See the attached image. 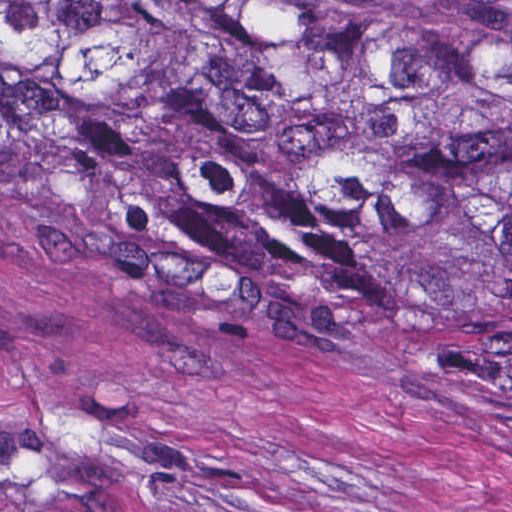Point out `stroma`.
Returning <instances> with one entry per match:
<instances>
[{
	"mask_svg": "<svg viewBox=\"0 0 512 512\" xmlns=\"http://www.w3.org/2000/svg\"><path fill=\"white\" fill-rule=\"evenodd\" d=\"M0 512H512V387L372 322L214 319L11 195L0 0Z\"/></svg>",
	"mask_w": 512,
	"mask_h": 512,
	"instance_id": "obj_1",
	"label": "stroma"
}]
</instances>
